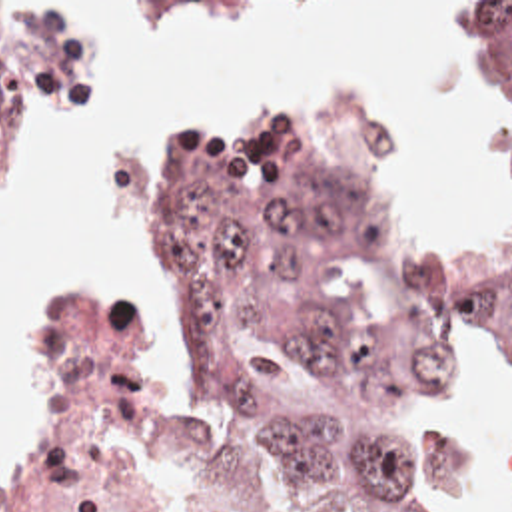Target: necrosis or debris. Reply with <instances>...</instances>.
<instances>
[{
  "mask_svg": "<svg viewBox=\"0 0 512 512\" xmlns=\"http://www.w3.org/2000/svg\"><path fill=\"white\" fill-rule=\"evenodd\" d=\"M123 297L65 313L55 449L0 512H223L197 375L155 317L111 301Z\"/></svg>",
  "mask_w": 512,
  "mask_h": 512,
  "instance_id": "4bbe7bcc",
  "label": "necrosis or debris"
}]
</instances>
